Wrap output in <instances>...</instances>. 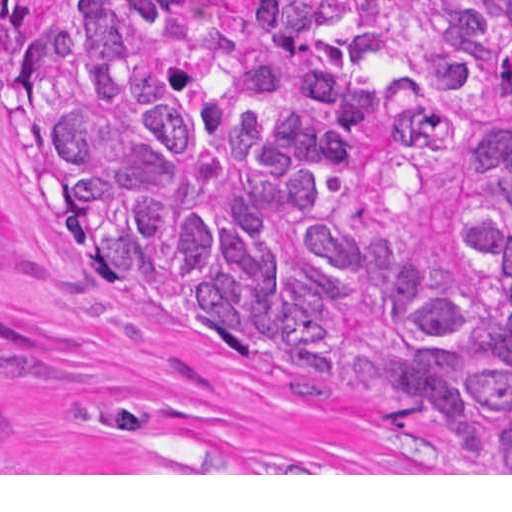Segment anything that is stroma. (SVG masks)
Here are the masks:
<instances>
[{"mask_svg": "<svg viewBox=\"0 0 512 512\" xmlns=\"http://www.w3.org/2000/svg\"><path fill=\"white\" fill-rule=\"evenodd\" d=\"M0 475L512 473L418 468L83 259L1 141L0 0Z\"/></svg>", "mask_w": 512, "mask_h": 512, "instance_id": "1", "label": "stroma"}]
</instances>
